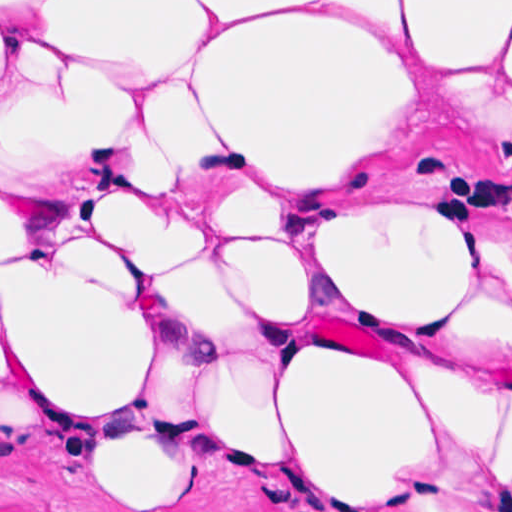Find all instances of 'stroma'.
<instances>
[{"instance_id": "1", "label": "stroma", "mask_w": 512, "mask_h": 512, "mask_svg": "<svg viewBox=\"0 0 512 512\" xmlns=\"http://www.w3.org/2000/svg\"><path fill=\"white\" fill-rule=\"evenodd\" d=\"M512 1V0H0ZM474 373L512 382V353L463 351ZM0 512H512L507 490L457 439L416 458L402 492L377 502L294 473L193 451L181 486L103 473L55 410L0 385Z\"/></svg>"}]
</instances>
